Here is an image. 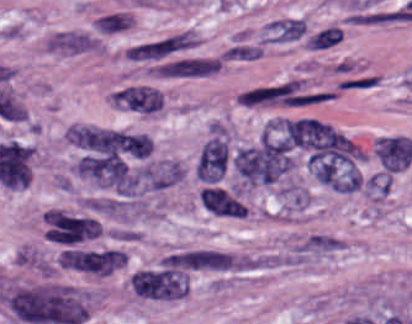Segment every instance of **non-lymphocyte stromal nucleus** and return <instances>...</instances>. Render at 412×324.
Masks as SVG:
<instances>
[{
	"label": "non-lymphocyte stromal nucleus",
	"mask_w": 412,
	"mask_h": 324,
	"mask_svg": "<svg viewBox=\"0 0 412 324\" xmlns=\"http://www.w3.org/2000/svg\"><path fill=\"white\" fill-rule=\"evenodd\" d=\"M128 15L111 12L101 14L93 21L94 31L99 34H115L127 27Z\"/></svg>",
	"instance_id": "2ac0efb1"
},
{
	"label": "non-lymphocyte stromal nucleus",
	"mask_w": 412,
	"mask_h": 324,
	"mask_svg": "<svg viewBox=\"0 0 412 324\" xmlns=\"http://www.w3.org/2000/svg\"><path fill=\"white\" fill-rule=\"evenodd\" d=\"M121 109L137 114H154L162 101L160 89L147 84H127L110 96Z\"/></svg>",
	"instance_id": "fc2b8d12"
},
{
	"label": "non-lymphocyte stromal nucleus",
	"mask_w": 412,
	"mask_h": 324,
	"mask_svg": "<svg viewBox=\"0 0 412 324\" xmlns=\"http://www.w3.org/2000/svg\"><path fill=\"white\" fill-rule=\"evenodd\" d=\"M227 156V144L221 137L214 136L206 141L195 167L199 181L217 183L226 168Z\"/></svg>",
	"instance_id": "81446118"
},
{
	"label": "non-lymphocyte stromal nucleus",
	"mask_w": 412,
	"mask_h": 324,
	"mask_svg": "<svg viewBox=\"0 0 412 324\" xmlns=\"http://www.w3.org/2000/svg\"><path fill=\"white\" fill-rule=\"evenodd\" d=\"M0 297L6 309L27 324H78L88 316L84 297L64 286L10 288Z\"/></svg>",
	"instance_id": "dd21d789"
},
{
	"label": "non-lymphocyte stromal nucleus",
	"mask_w": 412,
	"mask_h": 324,
	"mask_svg": "<svg viewBox=\"0 0 412 324\" xmlns=\"http://www.w3.org/2000/svg\"><path fill=\"white\" fill-rule=\"evenodd\" d=\"M339 242L332 237L315 234L306 237L303 242L299 245L298 249L307 255L333 251L338 247Z\"/></svg>",
	"instance_id": "616ff342"
},
{
	"label": "non-lymphocyte stromal nucleus",
	"mask_w": 412,
	"mask_h": 324,
	"mask_svg": "<svg viewBox=\"0 0 412 324\" xmlns=\"http://www.w3.org/2000/svg\"><path fill=\"white\" fill-rule=\"evenodd\" d=\"M232 162L245 182L270 183L284 173L289 158L286 146L262 136L236 150Z\"/></svg>",
	"instance_id": "a72fc3eb"
},
{
	"label": "non-lymphocyte stromal nucleus",
	"mask_w": 412,
	"mask_h": 324,
	"mask_svg": "<svg viewBox=\"0 0 412 324\" xmlns=\"http://www.w3.org/2000/svg\"><path fill=\"white\" fill-rule=\"evenodd\" d=\"M342 38L338 28L327 26L311 36L306 42V47L311 50H322L334 45Z\"/></svg>",
	"instance_id": "6412c185"
},
{
	"label": "non-lymphocyte stromal nucleus",
	"mask_w": 412,
	"mask_h": 324,
	"mask_svg": "<svg viewBox=\"0 0 412 324\" xmlns=\"http://www.w3.org/2000/svg\"><path fill=\"white\" fill-rule=\"evenodd\" d=\"M199 200L206 210L217 216H235V201L222 188H203Z\"/></svg>",
	"instance_id": "7c5642bf"
},
{
	"label": "non-lymphocyte stromal nucleus",
	"mask_w": 412,
	"mask_h": 324,
	"mask_svg": "<svg viewBox=\"0 0 412 324\" xmlns=\"http://www.w3.org/2000/svg\"><path fill=\"white\" fill-rule=\"evenodd\" d=\"M99 35L81 29H62L43 40L42 51L62 56H79L100 52Z\"/></svg>",
	"instance_id": "3746e769"
},
{
	"label": "non-lymphocyte stromal nucleus",
	"mask_w": 412,
	"mask_h": 324,
	"mask_svg": "<svg viewBox=\"0 0 412 324\" xmlns=\"http://www.w3.org/2000/svg\"><path fill=\"white\" fill-rule=\"evenodd\" d=\"M264 47L259 43L236 37L221 52L224 61H249L260 56Z\"/></svg>",
	"instance_id": "9d01c50a"
}]
</instances>
